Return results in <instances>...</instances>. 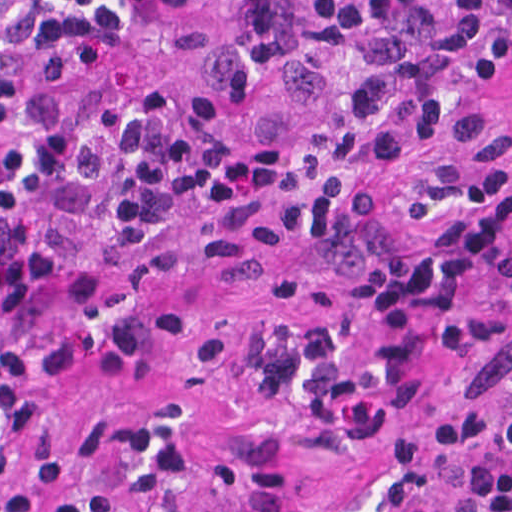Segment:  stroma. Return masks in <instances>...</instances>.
Here are the masks:
<instances>
[{"instance_id":"35a3bbf8","label":"stroma","mask_w":512,"mask_h":512,"mask_svg":"<svg viewBox=\"0 0 512 512\" xmlns=\"http://www.w3.org/2000/svg\"><path fill=\"white\" fill-rule=\"evenodd\" d=\"M210 40L195 52L106 44L69 82L74 101L129 89L208 93L241 146L285 150L282 183L256 219L179 217L127 283L110 271L73 215L52 219L59 263L52 312L99 329L84 355L50 379L47 414L75 460L77 492L90 434L117 409H158L211 437L217 461L235 427L243 367L264 334L297 311L330 306L341 280L308 266L301 187L310 154L351 86L346 64L299 30L295 0H203ZM463 65L470 117L447 150L392 163L378 189L390 215H445L474 196L484 163L512 157V89L487 80L486 30ZM512 360V261L487 289L402 344L379 385L354 408L307 427L286 477L258 512H345L440 383Z\"/></svg>"}]
</instances>
